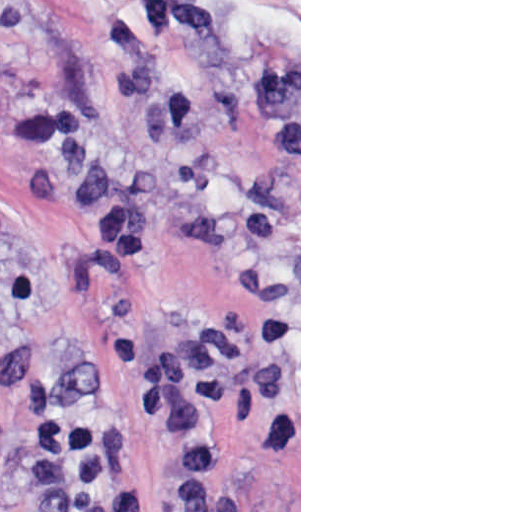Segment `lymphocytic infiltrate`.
I'll return each mask as SVG.
<instances>
[{
	"label": "lymphocytic infiltrate",
	"instance_id": "obj_1",
	"mask_svg": "<svg viewBox=\"0 0 512 512\" xmlns=\"http://www.w3.org/2000/svg\"><path fill=\"white\" fill-rule=\"evenodd\" d=\"M33 440L40 512H110L119 423L86 412L51 383L38 381L25 404Z\"/></svg>",
	"mask_w": 512,
	"mask_h": 512
}]
</instances>
